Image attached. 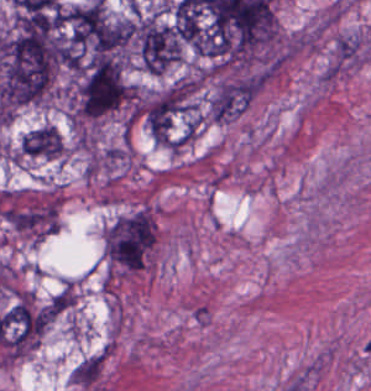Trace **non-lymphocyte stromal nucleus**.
<instances>
[{"label": "non-lymphocyte stromal nucleus", "instance_id": "dd21d789", "mask_svg": "<svg viewBox=\"0 0 371 391\" xmlns=\"http://www.w3.org/2000/svg\"><path fill=\"white\" fill-rule=\"evenodd\" d=\"M106 368L104 352H84L73 356L68 377L76 391H89L101 383Z\"/></svg>", "mask_w": 371, "mask_h": 391}]
</instances>
